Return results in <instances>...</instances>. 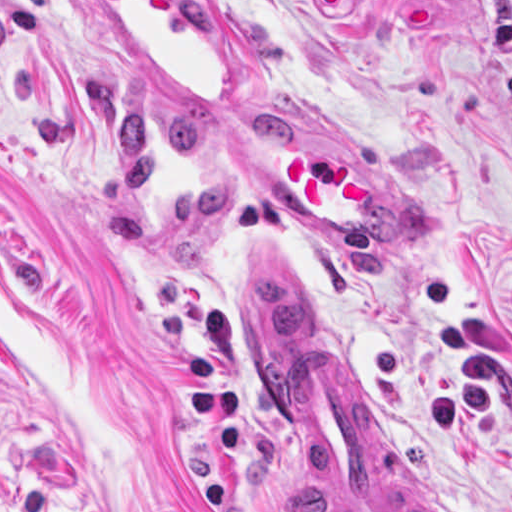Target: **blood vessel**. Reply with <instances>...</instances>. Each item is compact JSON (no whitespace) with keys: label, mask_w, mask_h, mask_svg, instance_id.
Wrapping results in <instances>:
<instances>
[{"label":"blood vessel","mask_w":512,"mask_h":512,"mask_svg":"<svg viewBox=\"0 0 512 512\" xmlns=\"http://www.w3.org/2000/svg\"><path fill=\"white\" fill-rule=\"evenodd\" d=\"M126 96L144 110H239L252 56L223 0H69ZM292 117L219 126L225 165L288 224L335 245H427L432 215L348 133ZM240 276L238 320L263 388L310 449L335 512H432L367 450L313 321L275 261Z\"/></svg>","instance_id":"8fb6f2fc"}]
</instances>
